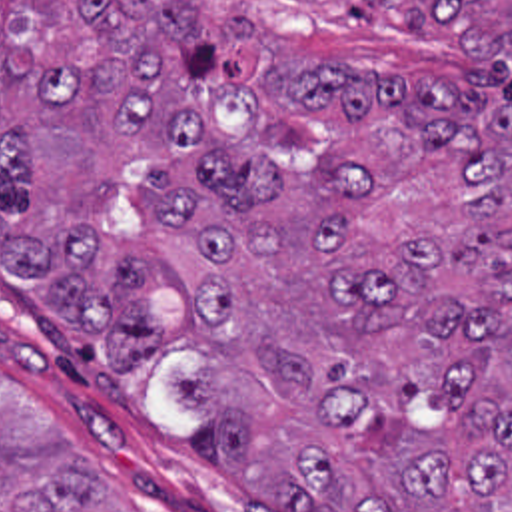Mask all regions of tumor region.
Segmentation results:
<instances>
[{
    "label": "tumor region",
    "mask_w": 512,
    "mask_h": 512,
    "mask_svg": "<svg viewBox=\"0 0 512 512\" xmlns=\"http://www.w3.org/2000/svg\"><path fill=\"white\" fill-rule=\"evenodd\" d=\"M0 261L284 512H512V0H0ZM0 512H129L1 377Z\"/></svg>",
    "instance_id": "tumor-region-1"
}]
</instances>
